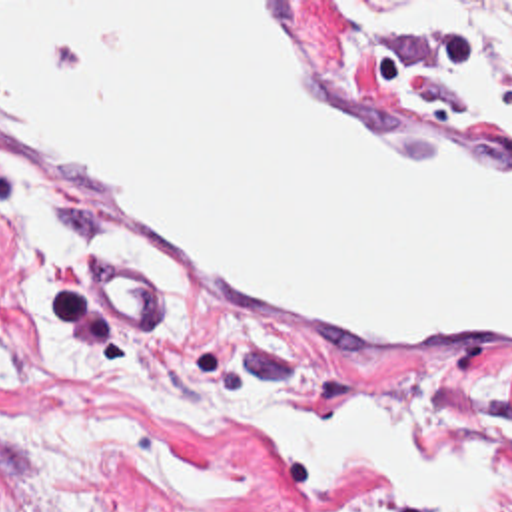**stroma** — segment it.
I'll use <instances>...</instances> for the list:
<instances>
[{
    "instance_id": "obj_1",
    "label": "stroma",
    "mask_w": 512,
    "mask_h": 512,
    "mask_svg": "<svg viewBox=\"0 0 512 512\" xmlns=\"http://www.w3.org/2000/svg\"><path fill=\"white\" fill-rule=\"evenodd\" d=\"M0 2H318L338 62L372 90L512 120V0ZM7 178L0 166V194ZM53 190L87 246L113 256ZM13 262L15 222L0 202V512H412L354 473L295 487L245 415L179 423L65 373L13 311L5 288ZM183 292L189 315L167 337L165 309L117 284L53 301V315L105 375L141 363L233 401L269 399L311 415L366 389L430 437L512 421V389L394 367L259 311ZM504 469L510 499L480 512H512V451Z\"/></svg>"
}]
</instances>
